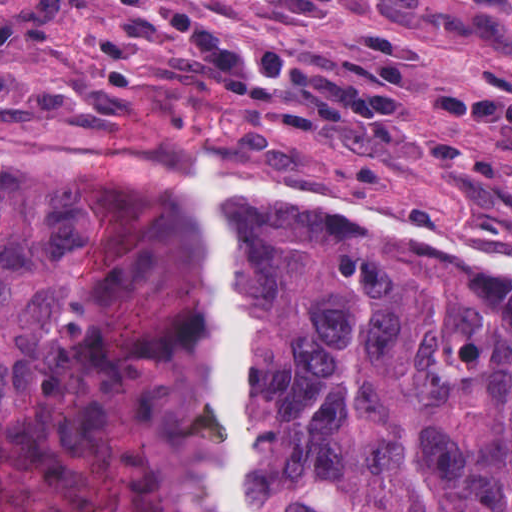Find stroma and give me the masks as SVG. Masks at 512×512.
<instances>
[{"mask_svg":"<svg viewBox=\"0 0 512 512\" xmlns=\"http://www.w3.org/2000/svg\"><path fill=\"white\" fill-rule=\"evenodd\" d=\"M203 1L228 33L261 50L330 46L349 58L369 53L381 25H398L418 46L413 133L327 126L239 97L189 44H171L166 27L149 32L114 0H68L49 35L0 41V151L54 168L196 176L212 147L234 184L250 185L246 172L327 180L463 239L512 241V216L443 164L438 141L481 159L512 160V144L418 109V92L433 87L512 94V0H376L321 20H269Z\"/></svg>","mask_w":512,"mask_h":512,"instance_id":"35a3bbf8","label":"stroma"}]
</instances>
